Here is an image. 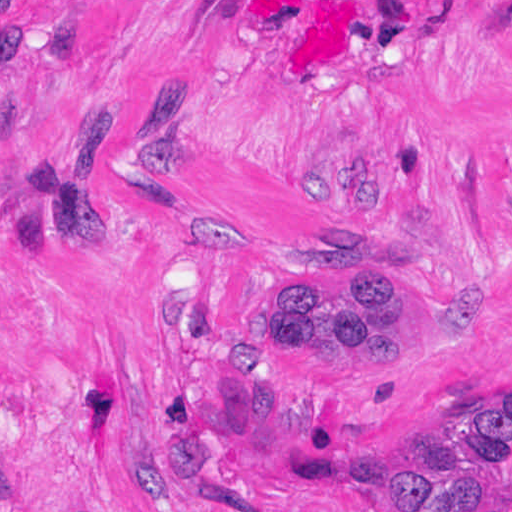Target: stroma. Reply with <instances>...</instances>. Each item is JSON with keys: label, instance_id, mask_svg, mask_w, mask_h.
Segmentation results:
<instances>
[{"label": "stroma", "instance_id": "stroma-1", "mask_svg": "<svg viewBox=\"0 0 512 512\" xmlns=\"http://www.w3.org/2000/svg\"><path fill=\"white\" fill-rule=\"evenodd\" d=\"M404 300L401 371L248 345ZM512 400V0H0V512H375Z\"/></svg>", "mask_w": 512, "mask_h": 512}]
</instances>
